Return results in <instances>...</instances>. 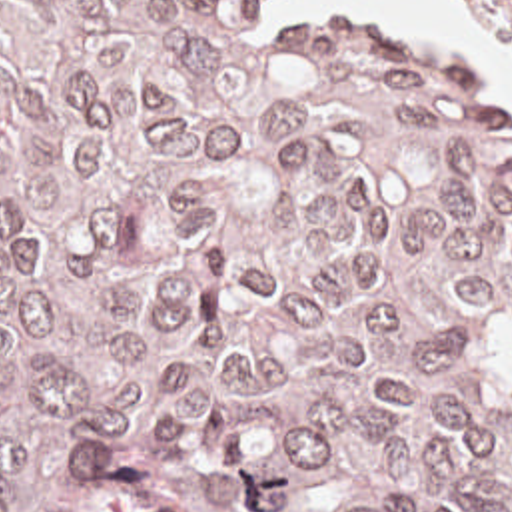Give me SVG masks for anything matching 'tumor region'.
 <instances>
[{
  "mask_svg": "<svg viewBox=\"0 0 512 512\" xmlns=\"http://www.w3.org/2000/svg\"><path fill=\"white\" fill-rule=\"evenodd\" d=\"M93 446L196 512H512V120L250 0H0V512Z\"/></svg>",
  "mask_w": 512,
  "mask_h": 512,
  "instance_id": "e687c5a6",
  "label": "tumor region"
}]
</instances>
